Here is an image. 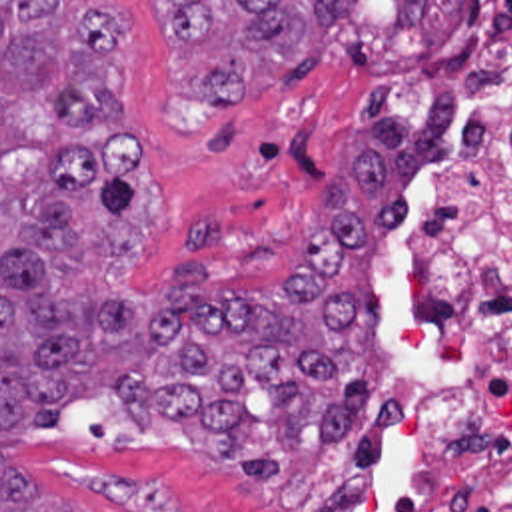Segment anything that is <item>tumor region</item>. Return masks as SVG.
Segmentation results:
<instances>
[{
    "label": "tumor region",
    "instance_id": "1",
    "mask_svg": "<svg viewBox=\"0 0 512 512\" xmlns=\"http://www.w3.org/2000/svg\"><path fill=\"white\" fill-rule=\"evenodd\" d=\"M178 50L250 20L230 56L198 66V94L244 106L302 52L348 36L362 0H154ZM396 20L441 52L467 0H394ZM130 20L110 0H0V512H86L32 485L6 453L64 423L68 403L114 395L150 427L214 429L222 459L280 475L244 451L258 421L246 395H276L286 445L328 439L368 389L380 312L374 254L394 230L412 124L388 78L358 104L350 166L322 184L316 230L290 248L282 282L214 292L196 260L144 270L166 220V188L130 122L122 60Z\"/></svg>",
    "mask_w": 512,
    "mask_h": 512
}]
</instances>
